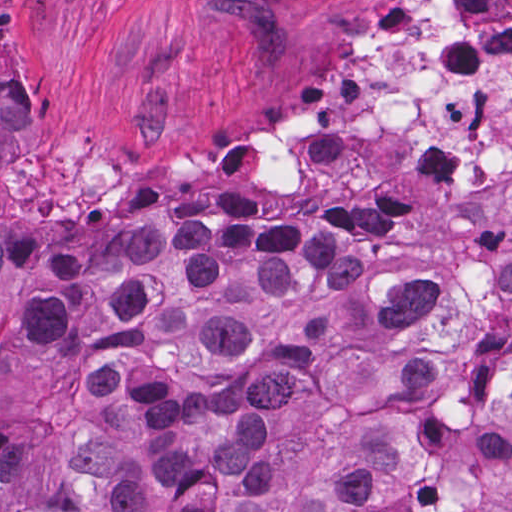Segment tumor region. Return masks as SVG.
I'll use <instances>...</instances> for the list:
<instances>
[{
	"label": "tumor region",
	"instance_id": "e687c5a6",
	"mask_svg": "<svg viewBox=\"0 0 512 512\" xmlns=\"http://www.w3.org/2000/svg\"><path fill=\"white\" fill-rule=\"evenodd\" d=\"M0 65V512H512V193L418 243L199 219L15 231Z\"/></svg>",
	"mask_w": 512,
	"mask_h": 512
}]
</instances>
